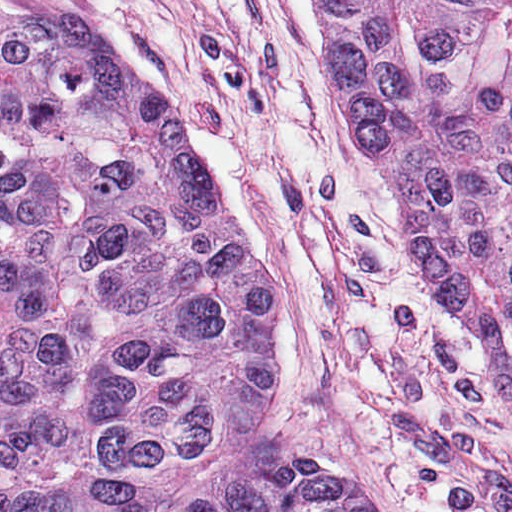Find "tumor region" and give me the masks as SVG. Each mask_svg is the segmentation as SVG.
<instances>
[{
    "mask_svg": "<svg viewBox=\"0 0 512 512\" xmlns=\"http://www.w3.org/2000/svg\"><path fill=\"white\" fill-rule=\"evenodd\" d=\"M424 304L512 373V0H315ZM278 299L189 134L61 11L0 7V512H160L270 417ZM201 512H390L331 462Z\"/></svg>",
    "mask_w": 512,
    "mask_h": 512,
    "instance_id": "e687c5a6",
    "label": "tumor region"
}]
</instances>
